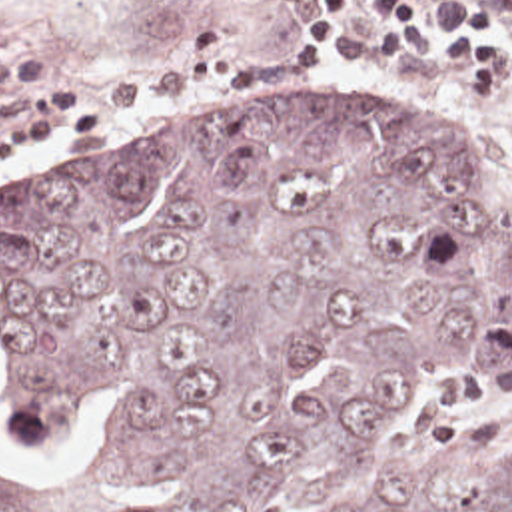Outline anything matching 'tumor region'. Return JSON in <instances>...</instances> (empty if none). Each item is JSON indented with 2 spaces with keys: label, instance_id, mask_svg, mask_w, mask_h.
Returning <instances> with one entry per match:
<instances>
[{
  "label": "tumor region",
  "instance_id": "tumor-region-1",
  "mask_svg": "<svg viewBox=\"0 0 512 512\" xmlns=\"http://www.w3.org/2000/svg\"><path fill=\"white\" fill-rule=\"evenodd\" d=\"M17 434L111 440L0 474V512H512V434L356 484L408 372L512 368V214L428 109L323 113L79 168L0 206Z\"/></svg>",
  "mask_w": 512,
  "mask_h": 512
}]
</instances>
